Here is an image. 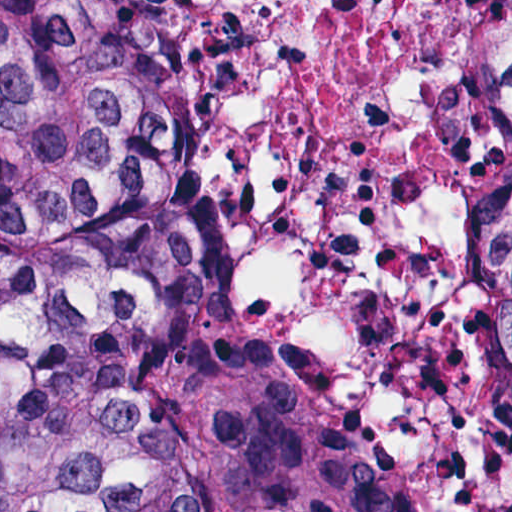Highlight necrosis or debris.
<instances>
[{"label":"necrosis or debris","mask_w":512,"mask_h":512,"mask_svg":"<svg viewBox=\"0 0 512 512\" xmlns=\"http://www.w3.org/2000/svg\"><path fill=\"white\" fill-rule=\"evenodd\" d=\"M208 121V305L411 512H512V0H153Z\"/></svg>","instance_id":"1"}]
</instances>
